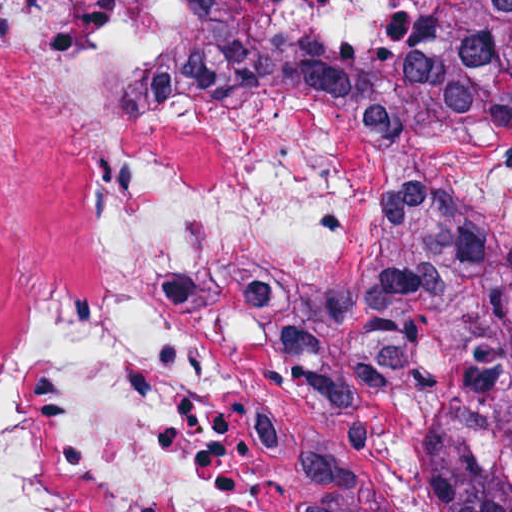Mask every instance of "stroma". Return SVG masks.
I'll return each mask as SVG.
<instances>
[{"instance_id":"1","label":"stroma","mask_w":512,"mask_h":512,"mask_svg":"<svg viewBox=\"0 0 512 512\" xmlns=\"http://www.w3.org/2000/svg\"><path fill=\"white\" fill-rule=\"evenodd\" d=\"M357 291L358 276L339 278L313 285L299 301L303 372L319 423L309 453V512H370L373 500L380 460L350 419L336 380V355Z\"/></svg>"}]
</instances>
